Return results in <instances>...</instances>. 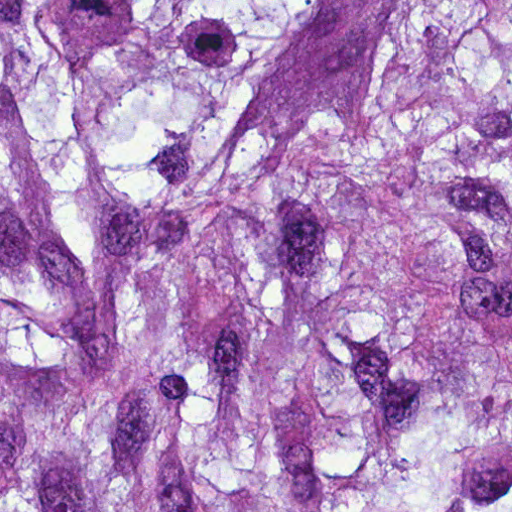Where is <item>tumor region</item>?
<instances>
[{"label": "tumor region", "mask_w": 512, "mask_h": 512, "mask_svg": "<svg viewBox=\"0 0 512 512\" xmlns=\"http://www.w3.org/2000/svg\"><path fill=\"white\" fill-rule=\"evenodd\" d=\"M0 512H512V0H0Z\"/></svg>", "instance_id": "tumor-region-1"}]
</instances>
